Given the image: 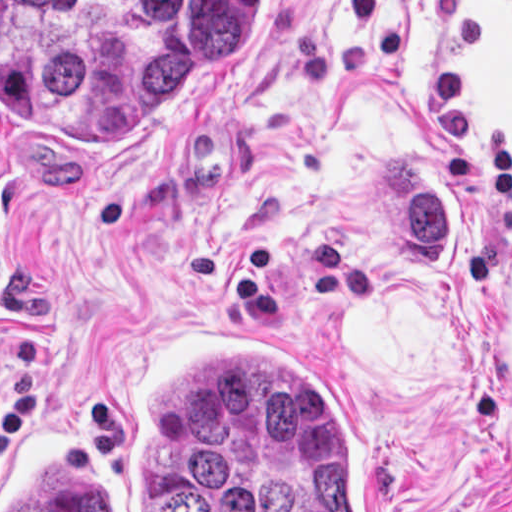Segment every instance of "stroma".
<instances>
[{"instance_id": "35a3bbf8", "label": "stroma", "mask_w": 512, "mask_h": 512, "mask_svg": "<svg viewBox=\"0 0 512 512\" xmlns=\"http://www.w3.org/2000/svg\"><path fill=\"white\" fill-rule=\"evenodd\" d=\"M406 145L442 167L423 155L448 273L408 267L376 215ZM165 325L320 363L394 512H512V0H255L243 66L148 116L116 50L65 108L0 0V512L1 431Z\"/></svg>"}]
</instances>
